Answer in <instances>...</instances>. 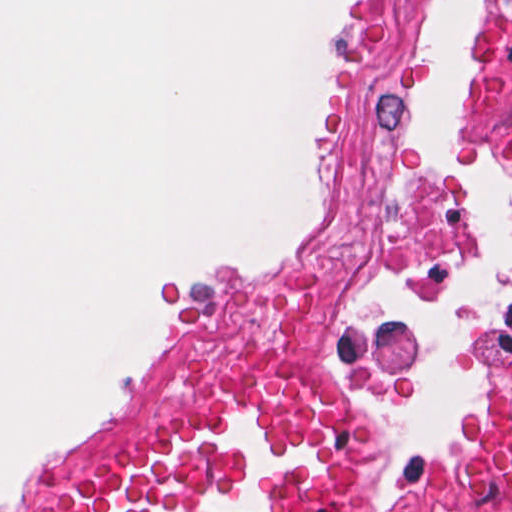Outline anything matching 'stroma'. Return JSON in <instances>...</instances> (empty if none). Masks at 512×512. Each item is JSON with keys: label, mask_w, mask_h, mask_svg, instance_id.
Instances as JSON below:
<instances>
[{"label": "stroma", "mask_w": 512, "mask_h": 512, "mask_svg": "<svg viewBox=\"0 0 512 512\" xmlns=\"http://www.w3.org/2000/svg\"><path fill=\"white\" fill-rule=\"evenodd\" d=\"M0 1H337L335 62L315 118L319 208L301 241L261 259L217 263L177 272L154 298L139 364L116 400L46 447L19 460L0 480V512H21L38 489L155 430L215 370L243 357L267 356L330 381L375 421L378 472L359 512H394L435 478L457 467L475 439V416L496 345L512 343V253L488 306L469 337V414L459 450L415 452L394 425V394L418 357L413 316L379 304L365 289L379 274L412 281H440L476 274L477 216L458 174L414 128V33L430 1H484L473 61L456 95L440 109L448 150L512 190V0H0ZM366 1H399L398 64L409 96L412 136L424 172L454 206L452 249L435 256H374L341 270L352 309L384 329L394 346V368L381 380L362 378L348 363L313 349H221L187 366L169 403L147 408L150 369L164 336L172 298L208 273L249 270L264 262L302 260L322 249L337 215V193L347 162V100L355 85L358 43L366 28Z\"/></svg>", "instance_id": "obj_1"}]
</instances>
